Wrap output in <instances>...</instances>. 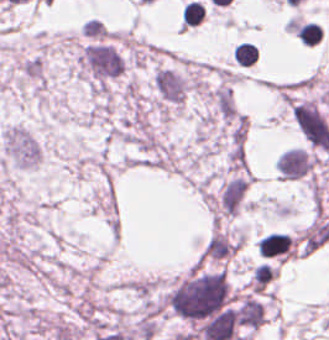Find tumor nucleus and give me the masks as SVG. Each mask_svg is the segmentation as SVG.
<instances>
[{
  "label": "tumor nucleus",
  "mask_w": 329,
  "mask_h": 340,
  "mask_svg": "<svg viewBox=\"0 0 329 340\" xmlns=\"http://www.w3.org/2000/svg\"><path fill=\"white\" fill-rule=\"evenodd\" d=\"M153 85L162 110L169 112L185 101L189 78L178 69L159 65L153 73Z\"/></svg>",
  "instance_id": "tumor-nucleus-1"
}]
</instances>
